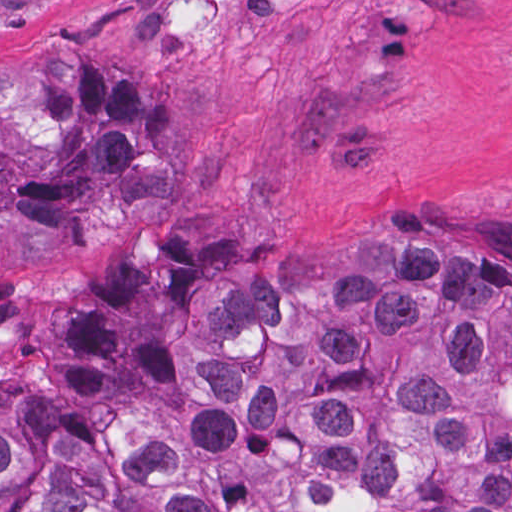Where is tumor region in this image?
I'll return each instance as SVG.
<instances>
[{
  "mask_svg": "<svg viewBox=\"0 0 512 512\" xmlns=\"http://www.w3.org/2000/svg\"><path fill=\"white\" fill-rule=\"evenodd\" d=\"M192 110L96 39L0 56V228L139 189ZM0 512H512V275L387 221L333 255L0 277Z\"/></svg>",
  "mask_w": 512,
  "mask_h": 512,
  "instance_id": "1",
  "label": "tumor region"
}]
</instances>
